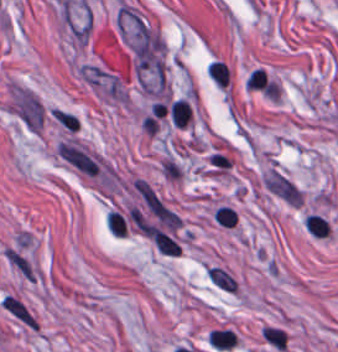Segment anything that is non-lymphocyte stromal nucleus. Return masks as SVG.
I'll return each mask as SVG.
<instances>
[{
	"mask_svg": "<svg viewBox=\"0 0 338 352\" xmlns=\"http://www.w3.org/2000/svg\"><path fill=\"white\" fill-rule=\"evenodd\" d=\"M12 105L23 124L37 131L43 115L38 98L25 88H17Z\"/></svg>",
	"mask_w": 338,
	"mask_h": 352,
	"instance_id": "non-lymphocyte-stromal-nucleus-1",
	"label": "non-lymphocyte stromal nucleus"
},
{
	"mask_svg": "<svg viewBox=\"0 0 338 352\" xmlns=\"http://www.w3.org/2000/svg\"><path fill=\"white\" fill-rule=\"evenodd\" d=\"M0 307L25 328L38 329L36 314L15 291H8L1 297Z\"/></svg>",
	"mask_w": 338,
	"mask_h": 352,
	"instance_id": "non-lymphocyte-stromal-nucleus-2",
	"label": "non-lymphocyte stromal nucleus"
},
{
	"mask_svg": "<svg viewBox=\"0 0 338 352\" xmlns=\"http://www.w3.org/2000/svg\"><path fill=\"white\" fill-rule=\"evenodd\" d=\"M264 183L268 190L285 203L299 205L302 193L300 189L287 178L270 169L264 179Z\"/></svg>",
	"mask_w": 338,
	"mask_h": 352,
	"instance_id": "non-lymphocyte-stromal-nucleus-3",
	"label": "non-lymphocyte stromal nucleus"
},
{
	"mask_svg": "<svg viewBox=\"0 0 338 352\" xmlns=\"http://www.w3.org/2000/svg\"><path fill=\"white\" fill-rule=\"evenodd\" d=\"M206 272L209 279L217 286L228 291H235L237 289L235 279L225 269L217 265H210L206 268Z\"/></svg>",
	"mask_w": 338,
	"mask_h": 352,
	"instance_id": "non-lymphocyte-stromal-nucleus-4",
	"label": "non-lymphocyte stromal nucleus"
}]
</instances>
